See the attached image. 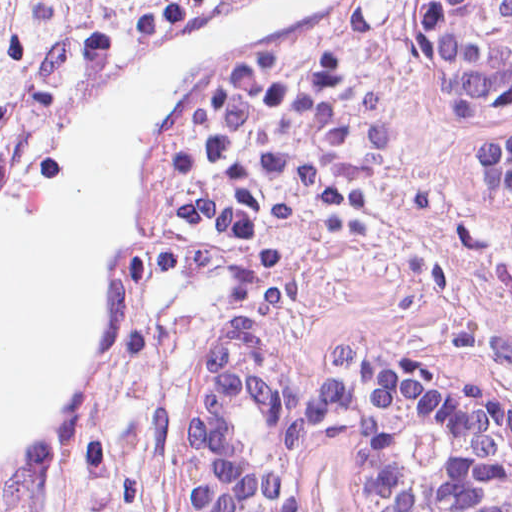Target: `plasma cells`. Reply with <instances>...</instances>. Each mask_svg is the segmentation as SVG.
Here are the masks:
<instances>
[{"mask_svg":"<svg viewBox=\"0 0 512 512\" xmlns=\"http://www.w3.org/2000/svg\"><path fill=\"white\" fill-rule=\"evenodd\" d=\"M390 156L379 103L338 56L273 53L221 78L172 143L147 307L175 326L241 330L276 265L373 188Z\"/></svg>","mask_w":512,"mask_h":512,"instance_id":"obj_1","label":"plasma cells"}]
</instances>
